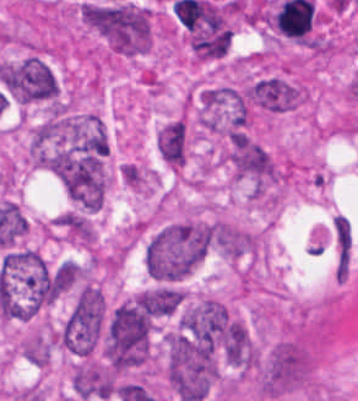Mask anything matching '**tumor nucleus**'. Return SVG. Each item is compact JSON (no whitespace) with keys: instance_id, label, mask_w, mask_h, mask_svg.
<instances>
[{"instance_id":"1","label":"tumor nucleus","mask_w":358,"mask_h":401,"mask_svg":"<svg viewBox=\"0 0 358 401\" xmlns=\"http://www.w3.org/2000/svg\"><path fill=\"white\" fill-rule=\"evenodd\" d=\"M107 151L98 115L62 106L50 110L29 141L34 163H98Z\"/></svg>"},{"instance_id":"2","label":"tumor nucleus","mask_w":358,"mask_h":401,"mask_svg":"<svg viewBox=\"0 0 358 401\" xmlns=\"http://www.w3.org/2000/svg\"><path fill=\"white\" fill-rule=\"evenodd\" d=\"M151 325V291L114 304L102 328L101 350L105 365L115 372L142 367L148 358Z\"/></svg>"},{"instance_id":"3","label":"tumor nucleus","mask_w":358,"mask_h":401,"mask_svg":"<svg viewBox=\"0 0 358 401\" xmlns=\"http://www.w3.org/2000/svg\"><path fill=\"white\" fill-rule=\"evenodd\" d=\"M206 251V226L172 221L156 228L142 252L144 271L161 282L180 280L202 260Z\"/></svg>"},{"instance_id":"4","label":"tumor nucleus","mask_w":358,"mask_h":401,"mask_svg":"<svg viewBox=\"0 0 358 401\" xmlns=\"http://www.w3.org/2000/svg\"><path fill=\"white\" fill-rule=\"evenodd\" d=\"M81 21L112 51L135 55L151 44V11L130 0L81 2Z\"/></svg>"},{"instance_id":"5","label":"tumor nucleus","mask_w":358,"mask_h":401,"mask_svg":"<svg viewBox=\"0 0 358 401\" xmlns=\"http://www.w3.org/2000/svg\"><path fill=\"white\" fill-rule=\"evenodd\" d=\"M227 319V306L211 296L183 309L166 334L168 361L212 356L221 346Z\"/></svg>"},{"instance_id":"6","label":"tumor nucleus","mask_w":358,"mask_h":401,"mask_svg":"<svg viewBox=\"0 0 358 401\" xmlns=\"http://www.w3.org/2000/svg\"><path fill=\"white\" fill-rule=\"evenodd\" d=\"M163 374L179 401H199L217 376L216 358L205 347L164 336Z\"/></svg>"},{"instance_id":"7","label":"tumor nucleus","mask_w":358,"mask_h":401,"mask_svg":"<svg viewBox=\"0 0 358 401\" xmlns=\"http://www.w3.org/2000/svg\"><path fill=\"white\" fill-rule=\"evenodd\" d=\"M312 370L313 355L304 335L286 339L270 347L258 363L255 386L265 398L301 387Z\"/></svg>"},{"instance_id":"8","label":"tumor nucleus","mask_w":358,"mask_h":401,"mask_svg":"<svg viewBox=\"0 0 358 401\" xmlns=\"http://www.w3.org/2000/svg\"><path fill=\"white\" fill-rule=\"evenodd\" d=\"M107 302L104 297H79L59 329L60 345L80 355H88L99 343Z\"/></svg>"},{"instance_id":"9","label":"tumor nucleus","mask_w":358,"mask_h":401,"mask_svg":"<svg viewBox=\"0 0 358 401\" xmlns=\"http://www.w3.org/2000/svg\"><path fill=\"white\" fill-rule=\"evenodd\" d=\"M226 158L236 177L263 187L276 175V162L266 147L244 133H231Z\"/></svg>"},{"instance_id":"10","label":"tumor nucleus","mask_w":358,"mask_h":401,"mask_svg":"<svg viewBox=\"0 0 358 401\" xmlns=\"http://www.w3.org/2000/svg\"><path fill=\"white\" fill-rule=\"evenodd\" d=\"M70 199L88 210L99 207L107 187L102 162H63L55 173Z\"/></svg>"},{"instance_id":"11","label":"tumor nucleus","mask_w":358,"mask_h":401,"mask_svg":"<svg viewBox=\"0 0 358 401\" xmlns=\"http://www.w3.org/2000/svg\"><path fill=\"white\" fill-rule=\"evenodd\" d=\"M254 103L266 111L283 112L299 104V87L281 76L265 75L254 81Z\"/></svg>"},{"instance_id":"12","label":"tumor nucleus","mask_w":358,"mask_h":401,"mask_svg":"<svg viewBox=\"0 0 358 401\" xmlns=\"http://www.w3.org/2000/svg\"><path fill=\"white\" fill-rule=\"evenodd\" d=\"M222 352L226 361L242 369L258 367V351L246 325L229 317L222 338Z\"/></svg>"},{"instance_id":"13","label":"tumor nucleus","mask_w":358,"mask_h":401,"mask_svg":"<svg viewBox=\"0 0 358 401\" xmlns=\"http://www.w3.org/2000/svg\"><path fill=\"white\" fill-rule=\"evenodd\" d=\"M157 151L164 163L184 164L188 149V127L179 114L166 120L155 134Z\"/></svg>"},{"instance_id":"14","label":"tumor nucleus","mask_w":358,"mask_h":401,"mask_svg":"<svg viewBox=\"0 0 358 401\" xmlns=\"http://www.w3.org/2000/svg\"><path fill=\"white\" fill-rule=\"evenodd\" d=\"M209 228L214 247L222 255L238 258L255 249L256 238L228 221L214 220Z\"/></svg>"},{"instance_id":"15","label":"tumor nucleus","mask_w":358,"mask_h":401,"mask_svg":"<svg viewBox=\"0 0 358 401\" xmlns=\"http://www.w3.org/2000/svg\"><path fill=\"white\" fill-rule=\"evenodd\" d=\"M150 312L155 317H168L178 312L185 300L184 290L162 285L146 288Z\"/></svg>"},{"instance_id":"16","label":"tumor nucleus","mask_w":358,"mask_h":401,"mask_svg":"<svg viewBox=\"0 0 358 401\" xmlns=\"http://www.w3.org/2000/svg\"><path fill=\"white\" fill-rule=\"evenodd\" d=\"M119 174L124 184L134 188H141L145 180V173L143 170L134 163L127 161L120 163Z\"/></svg>"}]
</instances>
